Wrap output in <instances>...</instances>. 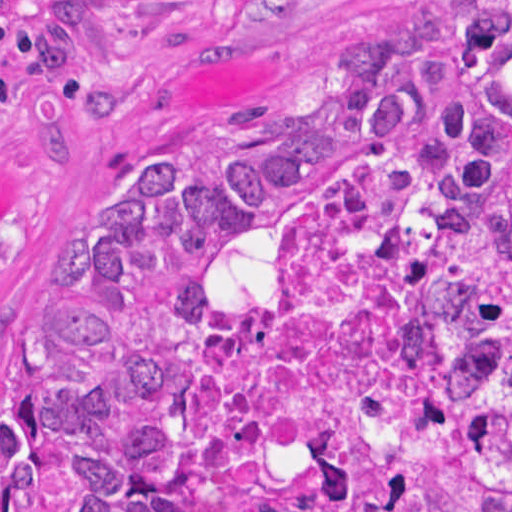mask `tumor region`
I'll use <instances>...</instances> for the list:
<instances>
[{
    "mask_svg": "<svg viewBox=\"0 0 512 512\" xmlns=\"http://www.w3.org/2000/svg\"><path fill=\"white\" fill-rule=\"evenodd\" d=\"M382 148L446 207L453 412L400 470L412 500L361 503L334 456L302 512H512V0L355 9L301 73L124 149L46 296L1 324V512H179L198 352L263 297L326 182Z\"/></svg>",
    "mask_w": 512,
    "mask_h": 512,
    "instance_id": "tumor-region-1",
    "label": "tumor region"
}]
</instances>
